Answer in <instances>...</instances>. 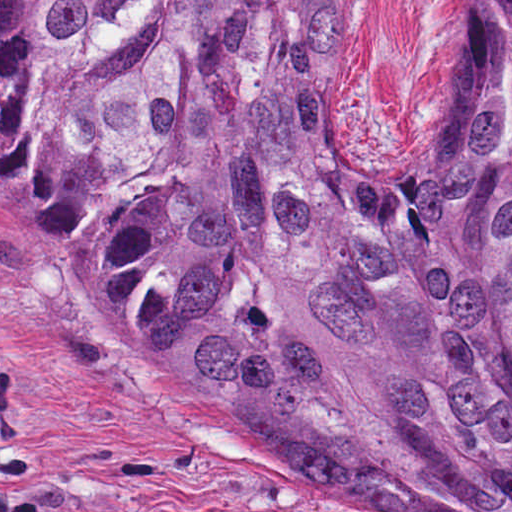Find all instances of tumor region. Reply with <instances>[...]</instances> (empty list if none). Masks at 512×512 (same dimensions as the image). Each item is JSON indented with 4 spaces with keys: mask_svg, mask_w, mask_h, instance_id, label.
<instances>
[{
    "mask_svg": "<svg viewBox=\"0 0 512 512\" xmlns=\"http://www.w3.org/2000/svg\"><path fill=\"white\" fill-rule=\"evenodd\" d=\"M357 0H0V232L345 512H512V0L428 149L348 161Z\"/></svg>",
    "mask_w": 512,
    "mask_h": 512,
    "instance_id": "obj_1",
    "label": "tumor region"
}]
</instances>
